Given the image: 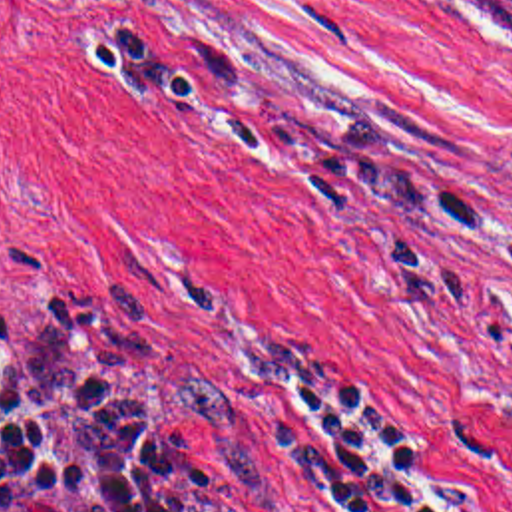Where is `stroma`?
Segmentation results:
<instances>
[{
    "label": "stroma",
    "mask_w": 512,
    "mask_h": 512,
    "mask_svg": "<svg viewBox=\"0 0 512 512\" xmlns=\"http://www.w3.org/2000/svg\"><path fill=\"white\" fill-rule=\"evenodd\" d=\"M134 31L260 115L512 218V0H0V292L110 328L182 512H278L250 439L280 334L335 356L463 512H512V232L375 202L144 103Z\"/></svg>",
    "instance_id": "obj_1"
}]
</instances>
